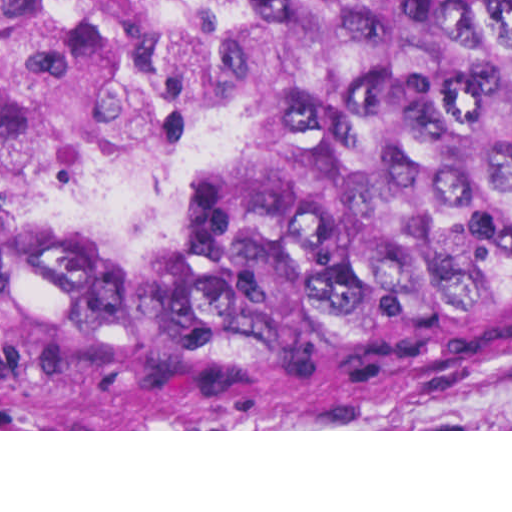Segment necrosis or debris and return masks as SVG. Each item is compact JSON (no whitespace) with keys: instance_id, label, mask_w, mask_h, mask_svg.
<instances>
[{"instance_id":"necrosis-or-debris-1","label":"necrosis or debris","mask_w":512,"mask_h":512,"mask_svg":"<svg viewBox=\"0 0 512 512\" xmlns=\"http://www.w3.org/2000/svg\"><path fill=\"white\" fill-rule=\"evenodd\" d=\"M0 114L38 204L151 217L226 154L183 0H0Z\"/></svg>"}]
</instances>
